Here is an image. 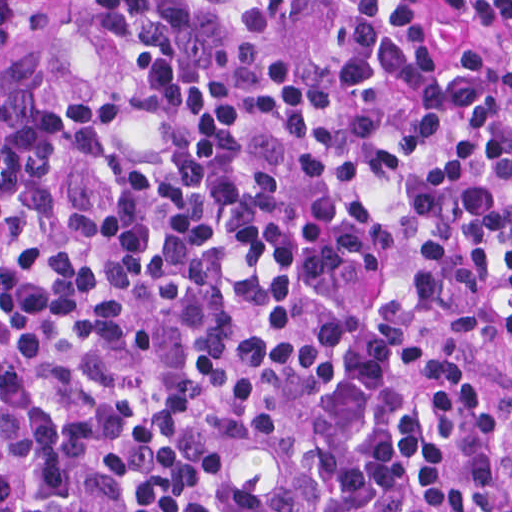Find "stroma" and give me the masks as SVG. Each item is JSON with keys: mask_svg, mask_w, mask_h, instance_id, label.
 <instances>
[{"mask_svg": "<svg viewBox=\"0 0 512 512\" xmlns=\"http://www.w3.org/2000/svg\"><path fill=\"white\" fill-rule=\"evenodd\" d=\"M401 335L420 351L468 373L502 406L505 475L512 477V355L450 327L405 312ZM0 512H1V0H0Z\"/></svg>", "mask_w": 512, "mask_h": 512, "instance_id": "1", "label": "stroma"}]
</instances>
